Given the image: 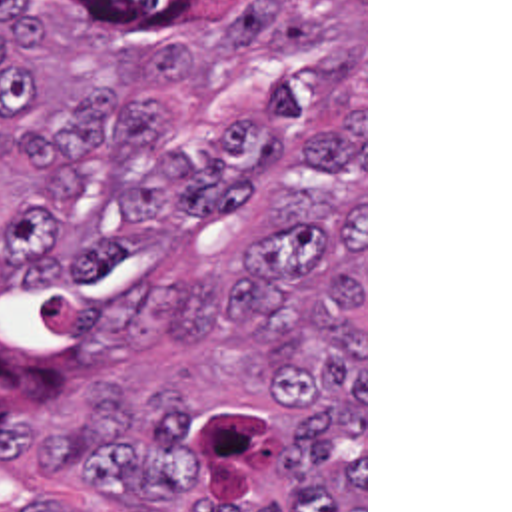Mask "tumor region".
Instances as JSON below:
<instances>
[{"label":"tumor region","instance_id":"tumor-region-1","mask_svg":"<svg viewBox=\"0 0 512 512\" xmlns=\"http://www.w3.org/2000/svg\"><path fill=\"white\" fill-rule=\"evenodd\" d=\"M92 14L88 60L136 96H86L59 134H29L35 186L5 216L7 284L63 286L120 258V232L212 228L280 180V148L250 124L180 148L162 108L270 122L304 146L262 212L254 248L190 282L168 360L254 336L286 382L272 459L278 507L218 509L192 451L184 395L90 387L33 431L23 473L94 491L86 512H364V0H61ZM29 0H0L1 142L39 118ZM11 512H61L33 495Z\"/></svg>","mask_w":512,"mask_h":512}]
</instances>
